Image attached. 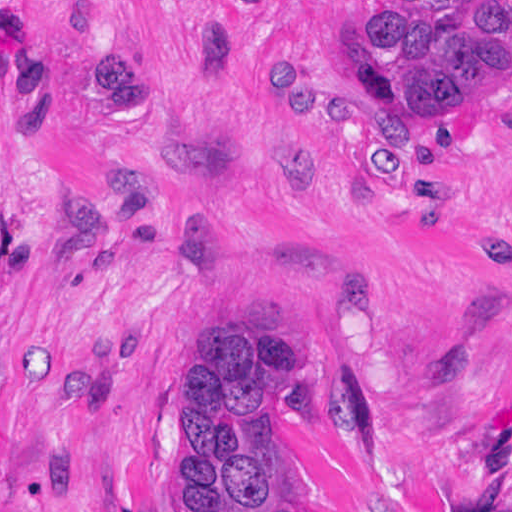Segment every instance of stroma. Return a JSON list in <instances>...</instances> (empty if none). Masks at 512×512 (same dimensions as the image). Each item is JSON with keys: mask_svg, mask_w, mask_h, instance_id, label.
<instances>
[{"mask_svg": "<svg viewBox=\"0 0 512 512\" xmlns=\"http://www.w3.org/2000/svg\"><path fill=\"white\" fill-rule=\"evenodd\" d=\"M375 0H0V512H176L174 409L227 314L305 347L273 410L303 512H512V91L380 121ZM133 42L154 125L82 45ZM292 50V119L259 63ZM323 187L259 191L289 138Z\"/></svg>", "mask_w": 512, "mask_h": 512, "instance_id": "obj_1", "label": "stroma"}]
</instances>
